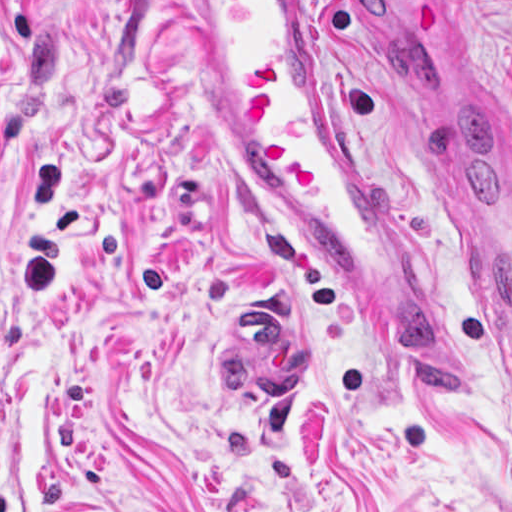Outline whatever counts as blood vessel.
<instances>
[{
    "label": "blood vessel",
    "instance_id": "blood-vessel-1",
    "mask_svg": "<svg viewBox=\"0 0 512 512\" xmlns=\"http://www.w3.org/2000/svg\"><path fill=\"white\" fill-rule=\"evenodd\" d=\"M198 70L226 138L311 256L457 402L470 373L419 279L394 191L373 162L306 27L305 1H188ZM466 153L437 173L439 211L478 267L512 359V189ZM233 307L219 353L253 397L298 402L312 352L294 323Z\"/></svg>",
    "mask_w": 512,
    "mask_h": 512
}]
</instances>
